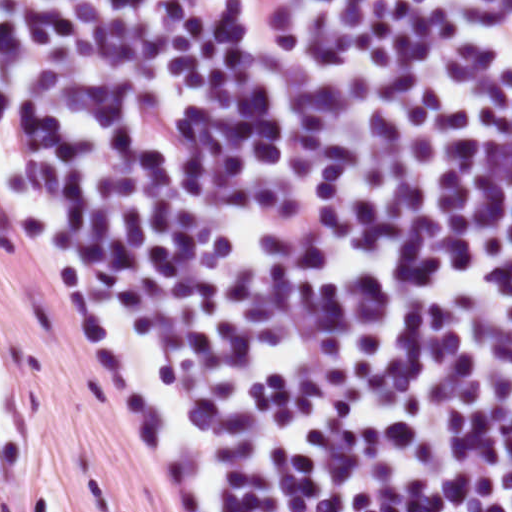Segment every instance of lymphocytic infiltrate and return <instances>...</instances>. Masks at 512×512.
<instances>
[{
  "label": "lymphocytic infiltrate",
  "instance_id": "1",
  "mask_svg": "<svg viewBox=\"0 0 512 512\" xmlns=\"http://www.w3.org/2000/svg\"><path fill=\"white\" fill-rule=\"evenodd\" d=\"M0 201L172 512H512V0H0Z\"/></svg>",
  "mask_w": 512,
  "mask_h": 512
}]
</instances>
